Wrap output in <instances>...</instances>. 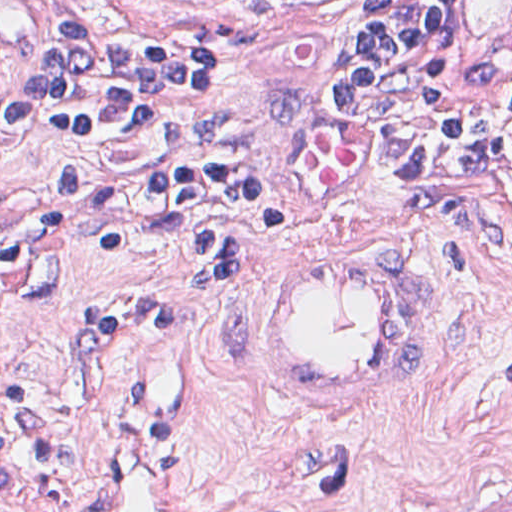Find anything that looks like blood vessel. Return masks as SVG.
I'll return each instance as SVG.
<instances>
[{
    "mask_svg": "<svg viewBox=\"0 0 512 512\" xmlns=\"http://www.w3.org/2000/svg\"><path fill=\"white\" fill-rule=\"evenodd\" d=\"M425 321L413 260L366 243H288L240 291L253 369L284 407L307 417L392 403L424 360ZM89 493L92 512H191L150 414H137L107 447Z\"/></svg>",
    "mask_w": 512,
    "mask_h": 512,
    "instance_id": "blood-vessel-1",
    "label": "blood vessel"
}]
</instances>
